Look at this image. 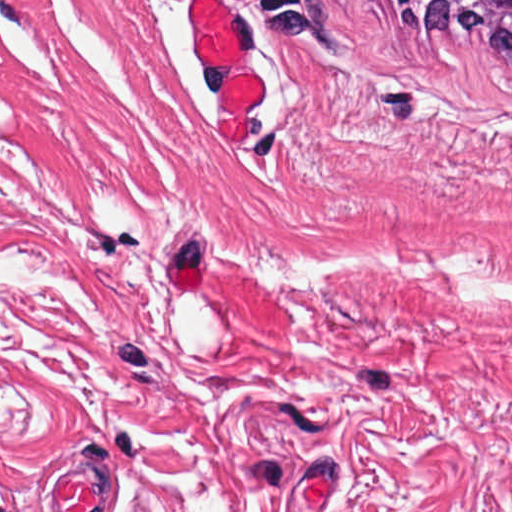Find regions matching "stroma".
<instances>
[{"mask_svg": "<svg viewBox=\"0 0 512 512\" xmlns=\"http://www.w3.org/2000/svg\"><path fill=\"white\" fill-rule=\"evenodd\" d=\"M36 0L0 342L512 396V59L373 0Z\"/></svg>", "mask_w": 512, "mask_h": 512, "instance_id": "1", "label": "stroma"}]
</instances>
